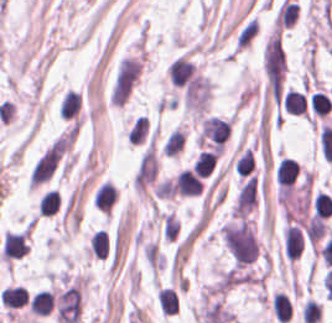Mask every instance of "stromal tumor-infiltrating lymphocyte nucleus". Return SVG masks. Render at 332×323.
Wrapping results in <instances>:
<instances>
[{"instance_id":"obj_1","label":"stromal tumor-infiltrating lymphocyte nucleus","mask_w":332,"mask_h":323,"mask_svg":"<svg viewBox=\"0 0 332 323\" xmlns=\"http://www.w3.org/2000/svg\"><path fill=\"white\" fill-rule=\"evenodd\" d=\"M282 238L284 254L289 259L292 260L300 255L304 247V238L300 228L288 222L283 228Z\"/></svg>"},{"instance_id":"obj_2","label":"stromal tumor-infiltrating lymphocyte nucleus","mask_w":332,"mask_h":323,"mask_svg":"<svg viewBox=\"0 0 332 323\" xmlns=\"http://www.w3.org/2000/svg\"><path fill=\"white\" fill-rule=\"evenodd\" d=\"M203 184L190 169H182L174 181V192L179 195L197 196Z\"/></svg>"},{"instance_id":"obj_3","label":"stromal tumor-infiltrating lymphocyte nucleus","mask_w":332,"mask_h":323,"mask_svg":"<svg viewBox=\"0 0 332 323\" xmlns=\"http://www.w3.org/2000/svg\"><path fill=\"white\" fill-rule=\"evenodd\" d=\"M299 169L290 156H283L275 165L274 176L278 188H289L295 181Z\"/></svg>"},{"instance_id":"obj_4","label":"stromal tumor-infiltrating lymphocyte nucleus","mask_w":332,"mask_h":323,"mask_svg":"<svg viewBox=\"0 0 332 323\" xmlns=\"http://www.w3.org/2000/svg\"><path fill=\"white\" fill-rule=\"evenodd\" d=\"M116 191L109 181H102L94 191L92 203L99 211L108 213L114 202Z\"/></svg>"},{"instance_id":"obj_5","label":"stromal tumor-infiltrating lymphocyte nucleus","mask_w":332,"mask_h":323,"mask_svg":"<svg viewBox=\"0 0 332 323\" xmlns=\"http://www.w3.org/2000/svg\"><path fill=\"white\" fill-rule=\"evenodd\" d=\"M0 301L11 309H18L28 302V295L21 285H8L0 292Z\"/></svg>"},{"instance_id":"obj_6","label":"stromal tumor-infiltrating lymphocyte nucleus","mask_w":332,"mask_h":323,"mask_svg":"<svg viewBox=\"0 0 332 323\" xmlns=\"http://www.w3.org/2000/svg\"><path fill=\"white\" fill-rule=\"evenodd\" d=\"M283 107L287 113H306L305 94L296 89H288L283 95Z\"/></svg>"},{"instance_id":"obj_7","label":"stromal tumor-infiltrating lymphocyte nucleus","mask_w":332,"mask_h":323,"mask_svg":"<svg viewBox=\"0 0 332 323\" xmlns=\"http://www.w3.org/2000/svg\"><path fill=\"white\" fill-rule=\"evenodd\" d=\"M53 294L46 289L34 292L30 299V312L37 315H47L51 310Z\"/></svg>"},{"instance_id":"obj_8","label":"stromal tumor-infiltrating lymphocyte nucleus","mask_w":332,"mask_h":323,"mask_svg":"<svg viewBox=\"0 0 332 323\" xmlns=\"http://www.w3.org/2000/svg\"><path fill=\"white\" fill-rule=\"evenodd\" d=\"M88 252L103 259L108 254V238L102 228L92 232L89 236Z\"/></svg>"},{"instance_id":"obj_9","label":"stromal tumor-infiltrating lymphocyte nucleus","mask_w":332,"mask_h":323,"mask_svg":"<svg viewBox=\"0 0 332 323\" xmlns=\"http://www.w3.org/2000/svg\"><path fill=\"white\" fill-rule=\"evenodd\" d=\"M331 104V98L327 93L317 89L311 92L309 97V106L316 115L326 116Z\"/></svg>"},{"instance_id":"obj_10","label":"stromal tumor-infiltrating lymphocyte nucleus","mask_w":332,"mask_h":323,"mask_svg":"<svg viewBox=\"0 0 332 323\" xmlns=\"http://www.w3.org/2000/svg\"><path fill=\"white\" fill-rule=\"evenodd\" d=\"M59 203V192L56 189L49 188L39 199L37 211L40 214L51 215L57 211Z\"/></svg>"},{"instance_id":"obj_11","label":"stromal tumor-infiltrating lymphocyte nucleus","mask_w":332,"mask_h":323,"mask_svg":"<svg viewBox=\"0 0 332 323\" xmlns=\"http://www.w3.org/2000/svg\"><path fill=\"white\" fill-rule=\"evenodd\" d=\"M254 158L253 154L247 148L241 152L232 165L233 172L236 175L248 176L253 172Z\"/></svg>"},{"instance_id":"obj_12","label":"stromal tumor-infiltrating lymphocyte nucleus","mask_w":332,"mask_h":323,"mask_svg":"<svg viewBox=\"0 0 332 323\" xmlns=\"http://www.w3.org/2000/svg\"><path fill=\"white\" fill-rule=\"evenodd\" d=\"M158 305L160 311L170 315L176 312L177 296L175 290L160 288L158 295Z\"/></svg>"},{"instance_id":"obj_13","label":"stromal tumor-infiltrating lymphocyte nucleus","mask_w":332,"mask_h":323,"mask_svg":"<svg viewBox=\"0 0 332 323\" xmlns=\"http://www.w3.org/2000/svg\"><path fill=\"white\" fill-rule=\"evenodd\" d=\"M314 216L324 218L332 213V199L325 191H318L313 201Z\"/></svg>"},{"instance_id":"obj_14","label":"stromal tumor-infiltrating lymphocyte nucleus","mask_w":332,"mask_h":323,"mask_svg":"<svg viewBox=\"0 0 332 323\" xmlns=\"http://www.w3.org/2000/svg\"><path fill=\"white\" fill-rule=\"evenodd\" d=\"M195 171H197L202 177L212 171L213 166L211 159H197L193 162L191 166Z\"/></svg>"}]
</instances>
